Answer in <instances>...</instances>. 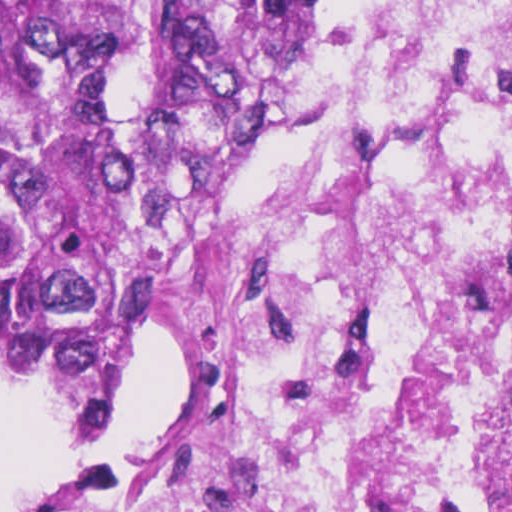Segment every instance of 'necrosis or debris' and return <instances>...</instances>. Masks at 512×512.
Listing matches in <instances>:
<instances>
[{"label":"necrosis or debris","instance_id":"4bbe7bcc","mask_svg":"<svg viewBox=\"0 0 512 512\" xmlns=\"http://www.w3.org/2000/svg\"><path fill=\"white\" fill-rule=\"evenodd\" d=\"M155 303L150 466L27 512H512V0H341Z\"/></svg>","mask_w":512,"mask_h":512}]
</instances>
